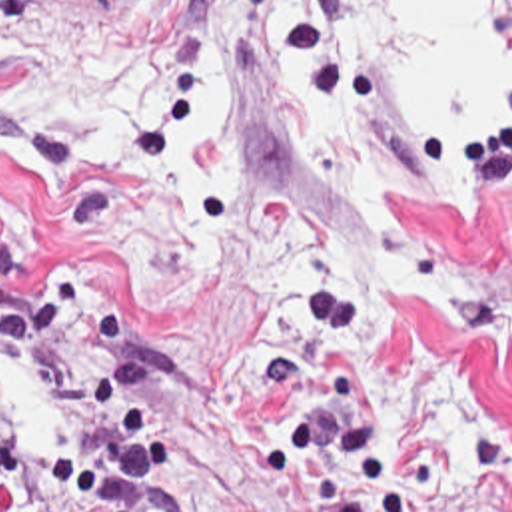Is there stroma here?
<instances>
[{"mask_svg": "<svg viewBox=\"0 0 512 512\" xmlns=\"http://www.w3.org/2000/svg\"><path fill=\"white\" fill-rule=\"evenodd\" d=\"M137 0H1L3 29L33 13L75 47H113ZM209 37L233 109V189L305 214L351 260L381 224L353 214L291 115L307 79L389 159L409 228L458 264V306L407 310L361 282L337 288L361 316L401 454L413 438L450 460L464 422L512 442V75L480 127H444L327 25L291 23L255 0H183V89L173 113L127 149L169 159L189 121L191 77ZM55 286H111L159 368L163 496L155 512H307L261 488L265 420L249 372L291 348L293 302L319 288L241 282L213 268L163 296L131 274L123 214L55 127L0 111V430L57 434L77 396L35 390L5 358L1 306Z\"/></svg>", "mask_w": 512, "mask_h": 512, "instance_id": "35a3bbf8", "label": "stroma"}]
</instances>
